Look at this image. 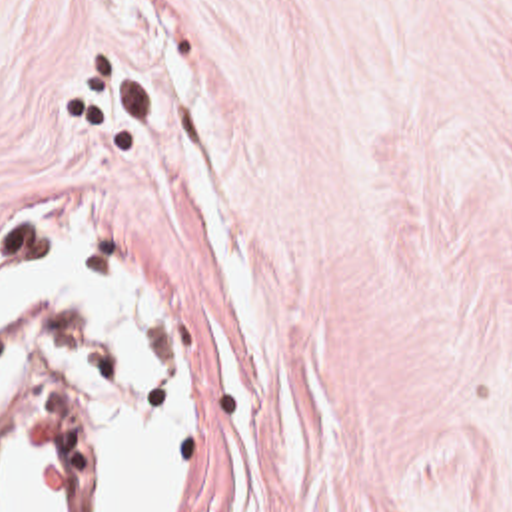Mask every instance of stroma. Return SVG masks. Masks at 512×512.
Instances as JSON below:
<instances>
[{
    "instance_id": "obj_1",
    "label": "stroma",
    "mask_w": 512,
    "mask_h": 512,
    "mask_svg": "<svg viewBox=\"0 0 512 512\" xmlns=\"http://www.w3.org/2000/svg\"><path fill=\"white\" fill-rule=\"evenodd\" d=\"M68 227L201 387L165 512H512V0H0V279ZM40 333L94 341V512L111 343Z\"/></svg>"
}]
</instances>
